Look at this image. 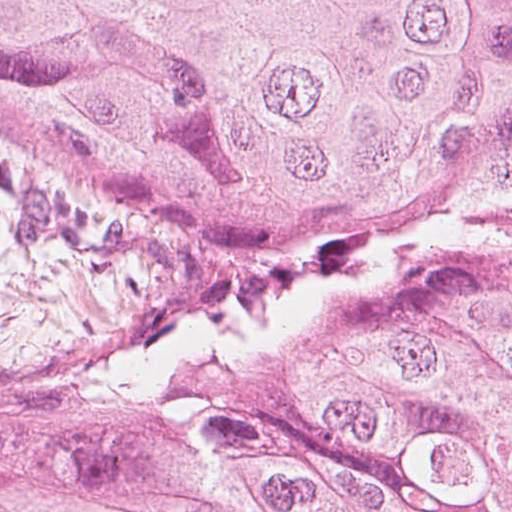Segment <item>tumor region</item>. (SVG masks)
<instances>
[{
    "label": "tumor region",
    "mask_w": 512,
    "mask_h": 512,
    "mask_svg": "<svg viewBox=\"0 0 512 512\" xmlns=\"http://www.w3.org/2000/svg\"><path fill=\"white\" fill-rule=\"evenodd\" d=\"M0 141L309 258L0 395V512H512V0H0Z\"/></svg>",
    "instance_id": "tumor-region-1"
}]
</instances>
